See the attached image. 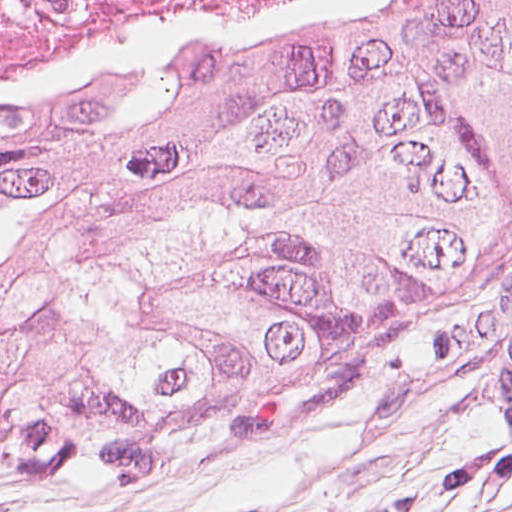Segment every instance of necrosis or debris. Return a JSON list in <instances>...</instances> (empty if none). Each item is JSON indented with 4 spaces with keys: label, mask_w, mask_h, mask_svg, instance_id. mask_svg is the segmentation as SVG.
<instances>
[{
    "label": "necrosis or debris",
    "mask_w": 512,
    "mask_h": 512,
    "mask_svg": "<svg viewBox=\"0 0 512 512\" xmlns=\"http://www.w3.org/2000/svg\"><path fill=\"white\" fill-rule=\"evenodd\" d=\"M437 0H0V114L124 95L178 57L200 59Z\"/></svg>",
    "instance_id": "1"
}]
</instances>
